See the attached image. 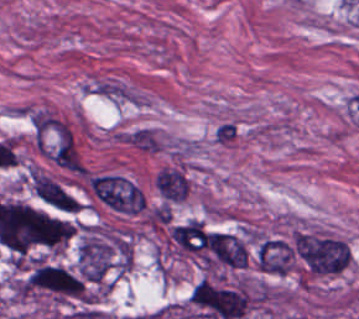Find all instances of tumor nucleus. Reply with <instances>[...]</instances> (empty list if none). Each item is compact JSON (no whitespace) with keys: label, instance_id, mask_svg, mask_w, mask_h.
I'll return each instance as SVG.
<instances>
[{"label":"tumor nucleus","instance_id":"2f306a5c","mask_svg":"<svg viewBox=\"0 0 359 319\" xmlns=\"http://www.w3.org/2000/svg\"><path fill=\"white\" fill-rule=\"evenodd\" d=\"M75 232L71 212L3 199L0 246L15 258L62 249Z\"/></svg>","mask_w":359,"mask_h":319},{"label":"tumor nucleus","instance_id":"8643909e","mask_svg":"<svg viewBox=\"0 0 359 319\" xmlns=\"http://www.w3.org/2000/svg\"><path fill=\"white\" fill-rule=\"evenodd\" d=\"M29 177L34 193L45 202L57 210L76 212V199L49 175L30 169Z\"/></svg>","mask_w":359,"mask_h":319}]
</instances>
